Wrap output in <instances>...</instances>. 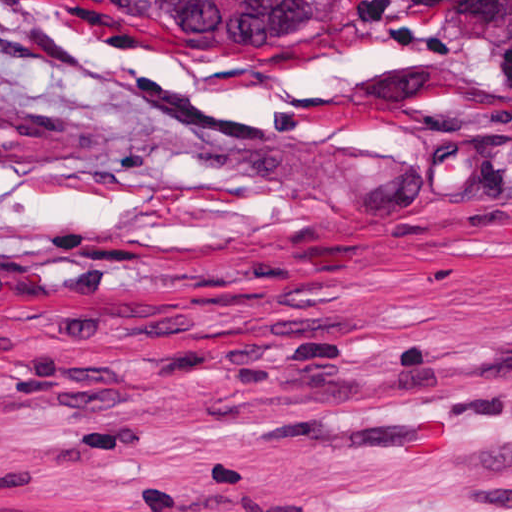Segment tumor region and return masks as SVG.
Wrapping results in <instances>:
<instances>
[{
    "label": "tumor region",
    "mask_w": 512,
    "mask_h": 512,
    "mask_svg": "<svg viewBox=\"0 0 512 512\" xmlns=\"http://www.w3.org/2000/svg\"><path fill=\"white\" fill-rule=\"evenodd\" d=\"M168 16H198L215 24L321 30L341 0H152Z\"/></svg>",
    "instance_id": "1"
}]
</instances>
